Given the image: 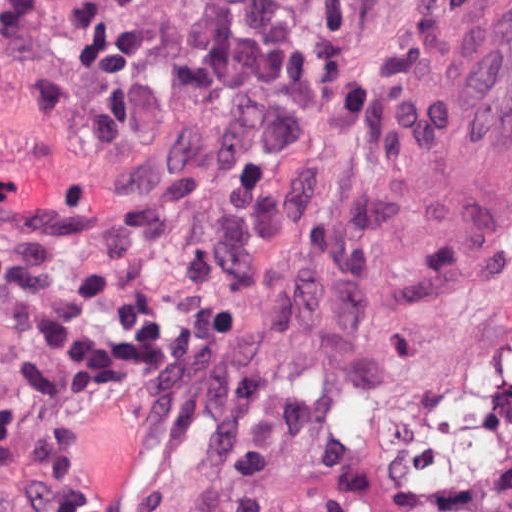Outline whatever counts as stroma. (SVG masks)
<instances>
[{
    "mask_svg": "<svg viewBox=\"0 0 512 512\" xmlns=\"http://www.w3.org/2000/svg\"><path fill=\"white\" fill-rule=\"evenodd\" d=\"M84 0H0V213L65 217L157 282L162 329L73 408L93 512H512V0H280L307 106L159 79L89 164L35 82L82 85ZM1 215V214H0Z\"/></svg>",
    "mask_w": 512,
    "mask_h": 512,
    "instance_id": "35a3bbf8",
    "label": "stroma"
}]
</instances>
